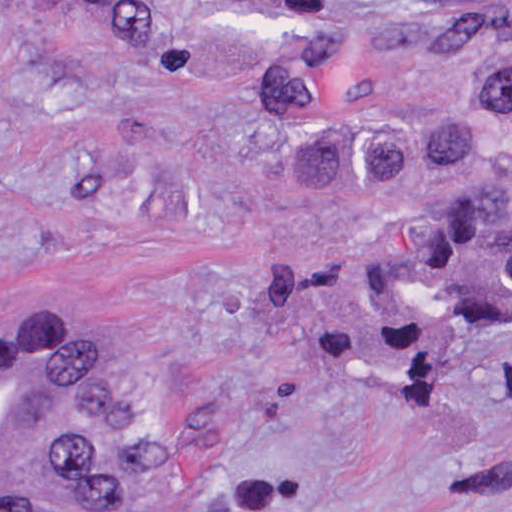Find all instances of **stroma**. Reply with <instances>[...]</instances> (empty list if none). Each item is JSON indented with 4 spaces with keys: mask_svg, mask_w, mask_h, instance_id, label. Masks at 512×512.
I'll return each instance as SVG.
<instances>
[{
    "mask_svg": "<svg viewBox=\"0 0 512 512\" xmlns=\"http://www.w3.org/2000/svg\"><path fill=\"white\" fill-rule=\"evenodd\" d=\"M311 1L512 0H0V339L99 286L158 473L239 512H512V316L411 350L372 298L384 240L487 174L290 186L266 137Z\"/></svg>",
    "mask_w": 512,
    "mask_h": 512,
    "instance_id": "obj_1",
    "label": "stroma"
}]
</instances>
